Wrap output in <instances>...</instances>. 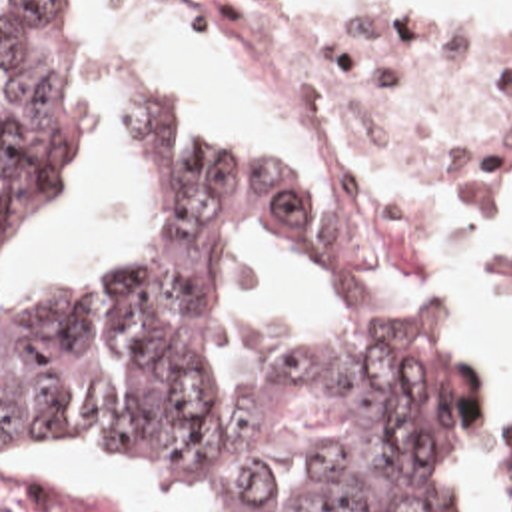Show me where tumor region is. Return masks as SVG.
Returning <instances> with one entry per match:
<instances>
[{
    "instance_id": "e687c5a6",
    "label": "tumor region",
    "mask_w": 512,
    "mask_h": 512,
    "mask_svg": "<svg viewBox=\"0 0 512 512\" xmlns=\"http://www.w3.org/2000/svg\"><path fill=\"white\" fill-rule=\"evenodd\" d=\"M116 69L56 0H2V241L52 191L50 99ZM174 193L130 267L34 313L2 309V408L22 440L120 450L196 512H453L489 422L463 336L391 307H347L335 338L304 326L244 396L218 402L212 261L240 215L288 227L310 261L325 227L266 139L214 157L166 115L130 125ZM2 512H134L56 474H2Z\"/></svg>"
}]
</instances>
